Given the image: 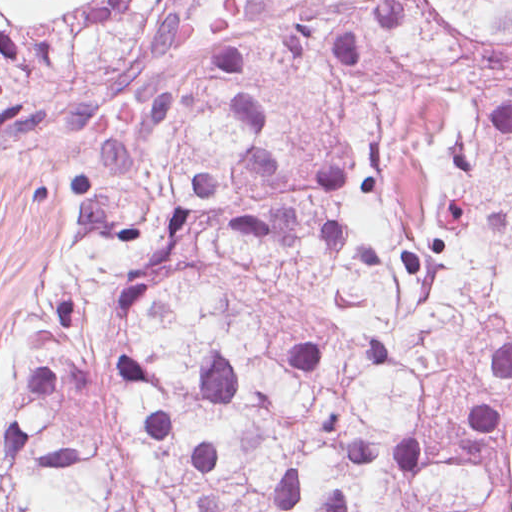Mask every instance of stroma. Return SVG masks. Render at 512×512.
<instances>
[{"mask_svg": "<svg viewBox=\"0 0 512 512\" xmlns=\"http://www.w3.org/2000/svg\"><path fill=\"white\" fill-rule=\"evenodd\" d=\"M79 129L45 152L0 157V402L27 308L54 294L75 214Z\"/></svg>", "mask_w": 512, "mask_h": 512, "instance_id": "35a3bbf8", "label": "stroma"}]
</instances>
